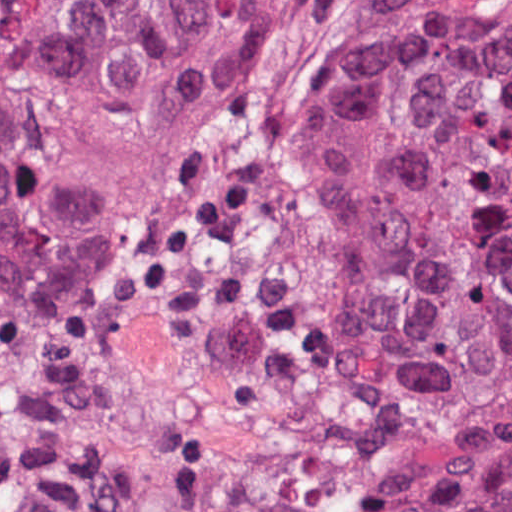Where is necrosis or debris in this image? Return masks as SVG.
I'll return each mask as SVG.
<instances>
[{
    "label": "necrosis or debris",
    "instance_id": "necrosis-or-debris-1",
    "mask_svg": "<svg viewBox=\"0 0 512 512\" xmlns=\"http://www.w3.org/2000/svg\"><path fill=\"white\" fill-rule=\"evenodd\" d=\"M0 512H426L327 405L148 323L0 314Z\"/></svg>",
    "mask_w": 512,
    "mask_h": 512
}]
</instances>
